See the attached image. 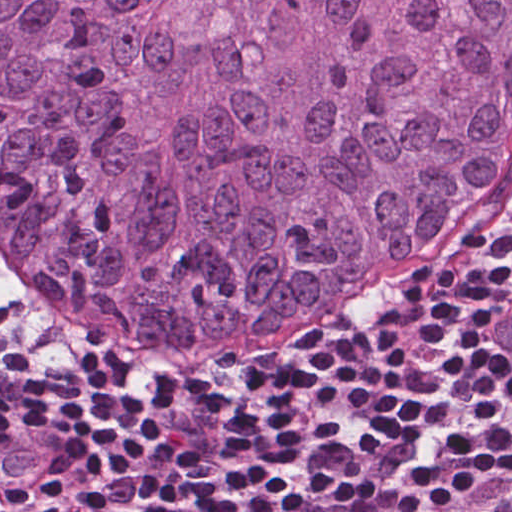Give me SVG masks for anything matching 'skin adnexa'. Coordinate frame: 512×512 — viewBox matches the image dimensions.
Returning <instances> with one entry per match:
<instances>
[{
  "instance_id": "1",
  "label": "skin adnexa",
  "mask_w": 512,
  "mask_h": 512,
  "mask_svg": "<svg viewBox=\"0 0 512 512\" xmlns=\"http://www.w3.org/2000/svg\"><path fill=\"white\" fill-rule=\"evenodd\" d=\"M512 149V0H0V290L136 344L299 324Z\"/></svg>"
}]
</instances>
